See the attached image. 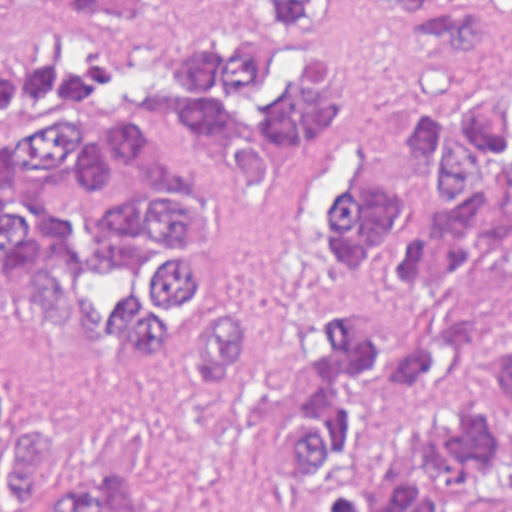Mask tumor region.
I'll return each mask as SVG.
<instances>
[{
  "mask_svg": "<svg viewBox=\"0 0 512 512\" xmlns=\"http://www.w3.org/2000/svg\"><path fill=\"white\" fill-rule=\"evenodd\" d=\"M360 31L356 1H1V512H164L117 458L58 481L43 422L12 396L24 301L98 356L171 348L186 398L215 399L313 259L402 291L458 263L512 269L511 61L416 89L383 162L329 163L271 293L192 282L204 199L160 123L254 188L290 184L342 137L338 65ZM458 392L443 332L403 340L365 297L327 299L270 463L313 512H512V346L381 482L359 475L361 419Z\"/></svg>",
  "mask_w": 512,
  "mask_h": 512,
  "instance_id": "tumor-region-1",
  "label": "tumor region"
}]
</instances>
